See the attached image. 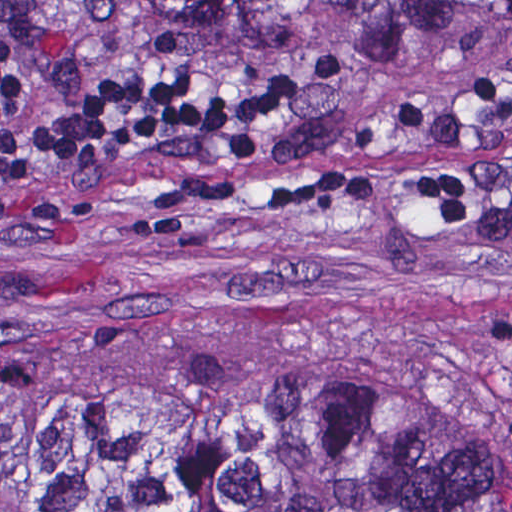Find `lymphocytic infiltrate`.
<instances>
[{"instance_id":"1","label":"lymphocytic infiltrate","mask_w":512,"mask_h":512,"mask_svg":"<svg viewBox=\"0 0 512 512\" xmlns=\"http://www.w3.org/2000/svg\"><path fill=\"white\" fill-rule=\"evenodd\" d=\"M58 0H0V194L46 187L104 145L164 125L211 149H236L254 136L268 101L227 74L137 80L116 90L84 86L51 43ZM512 5V0H509ZM408 193L450 229L474 219V170L427 177L338 159L263 192L258 215L318 211L340 203Z\"/></svg>"}]
</instances>
